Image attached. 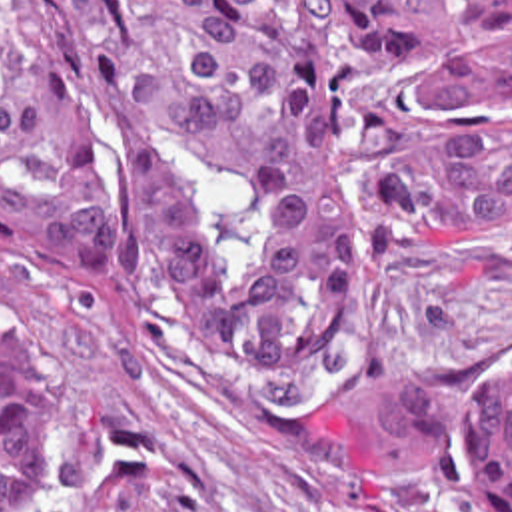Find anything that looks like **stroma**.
<instances>
[{
  "label": "stroma",
  "instance_id": "35a3bbf8",
  "mask_svg": "<svg viewBox=\"0 0 512 512\" xmlns=\"http://www.w3.org/2000/svg\"><path fill=\"white\" fill-rule=\"evenodd\" d=\"M0 356L51 448L41 512H498L482 398L512 382V218L390 266L360 342L302 378L204 370L164 264L57 268L0 236Z\"/></svg>",
  "mask_w": 512,
  "mask_h": 512
}]
</instances>
